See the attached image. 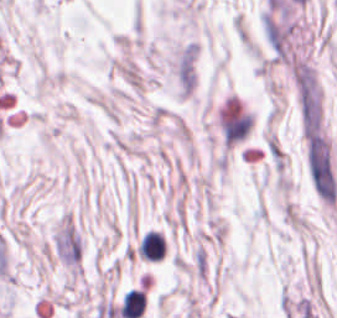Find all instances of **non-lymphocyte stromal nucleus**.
<instances>
[{
    "label": "non-lymphocyte stromal nucleus",
    "mask_w": 337,
    "mask_h": 318,
    "mask_svg": "<svg viewBox=\"0 0 337 318\" xmlns=\"http://www.w3.org/2000/svg\"><path fill=\"white\" fill-rule=\"evenodd\" d=\"M304 164L314 195L328 206H335L337 177L331 145L322 130L315 126L304 133Z\"/></svg>",
    "instance_id": "1"
}]
</instances>
